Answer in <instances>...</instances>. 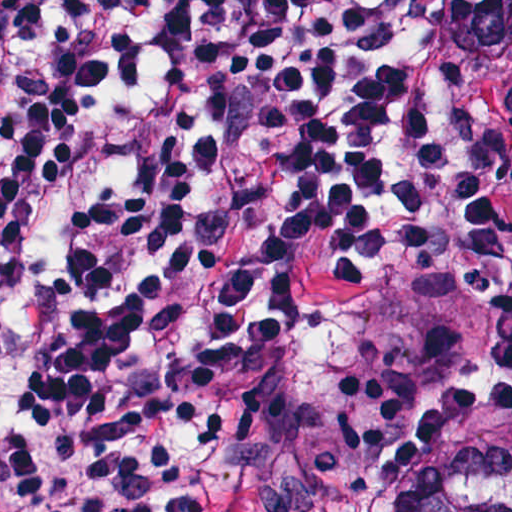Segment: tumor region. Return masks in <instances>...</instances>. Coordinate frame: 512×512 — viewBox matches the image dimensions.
Listing matches in <instances>:
<instances>
[{
	"label": "tumor region",
	"mask_w": 512,
	"mask_h": 512,
	"mask_svg": "<svg viewBox=\"0 0 512 512\" xmlns=\"http://www.w3.org/2000/svg\"><path fill=\"white\" fill-rule=\"evenodd\" d=\"M442 23L462 49L511 60L512 0H449ZM430 25L427 0L421 69L437 96L423 71ZM451 294L293 286L274 352L290 382L191 387L220 461L219 512H512V448L466 450L398 488L375 480L391 425L429 383Z\"/></svg>",
	"instance_id": "e687c5a6"
}]
</instances>
